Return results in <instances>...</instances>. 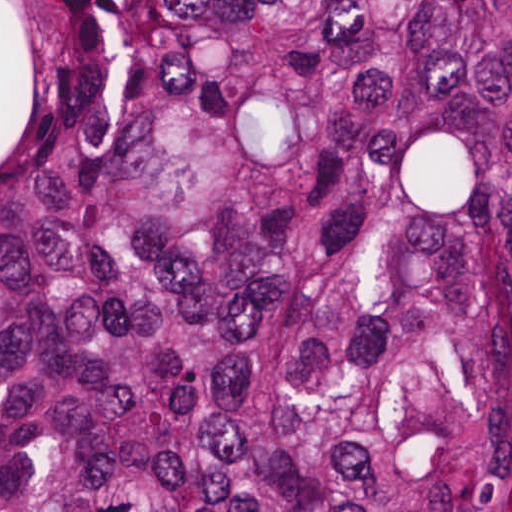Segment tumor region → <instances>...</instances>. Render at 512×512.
<instances>
[{
    "mask_svg": "<svg viewBox=\"0 0 512 512\" xmlns=\"http://www.w3.org/2000/svg\"><path fill=\"white\" fill-rule=\"evenodd\" d=\"M0 512H512V1H89L29 36Z\"/></svg>",
    "mask_w": 512,
    "mask_h": 512,
    "instance_id": "e687c5a6",
    "label": "tumor region"
}]
</instances>
